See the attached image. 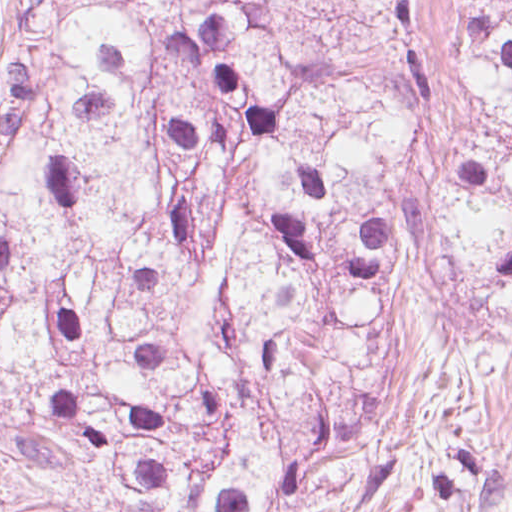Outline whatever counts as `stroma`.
Masks as SVG:
<instances>
[{
    "mask_svg": "<svg viewBox=\"0 0 512 512\" xmlns=\"http://www.w3.org/2000/svg\"><path fill=\"white\" fill-rule=\"evenodd\" d=\"M245 1L269 44L405 97L428 124L435 158L482 121L449 0ZM25 3L0 0V92ZM394 274L406 397L466 415L483 450L481 490L451 512H512V334L480 325L436 224L402 244Z\"/></svg>",
    "mask_w": 512,
    "mask_h": 512,
    "instance_id": "stroma-1",
    "label": "stroma"
}]
</instances>
